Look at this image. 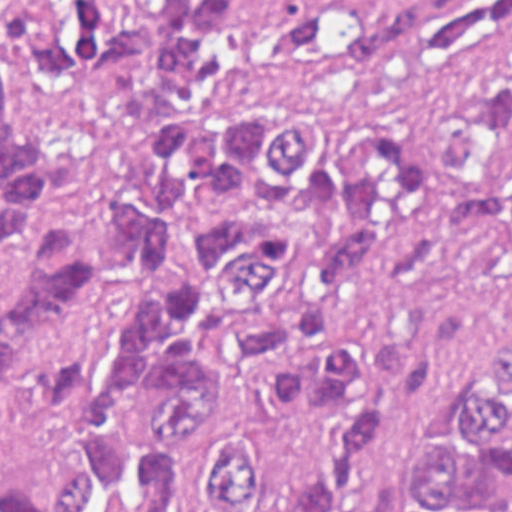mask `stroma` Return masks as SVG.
<instances>
[{
	"instance_id": "35a3bbf8",
	"label": "stroma",
	"mask_w": 512,
	"mask_h": 512,
	"mask_svg": "<svg viewBox=\"0 0 512 512\" xmlns=\"http://www.w3.org/2000/svg\"><path fill=\"white\" fill-rule=\"evenodd\" d=\"M512 37V18L460 39L425 65L360 57L344 65H240L250 85L337 106L375 135L413 150L417 195L382 246L375 272L332 303L340 324L382 327L428 303H452L468 320L430 382L413 394L387 457L343 512H390L407 486L433 420L457 388L512 337V265L501 233L463 249L446 237L442 168L468 154L474 89L484 64Z\"/></svg>"
}]
</instances>
